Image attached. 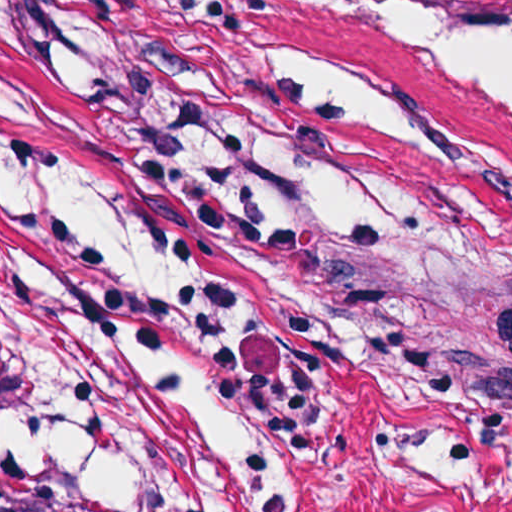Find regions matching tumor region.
Returning a JSON list of instances; mask_svg holds the SVG:
<instances>
[{"instance_id":"1","label":"tumor region","mask_w":512,"mask_h":512,"mask_svg":"<svg viewBox=\"0 0 512 512\" xmlns=\"http://www.w3.org/2000/svg\"><path fill=\"white\" fill-rule=\"evenodd\" d=\"M294 276L315 284L316 262L355 260L306 249L290 256ZM457 279L488 291L512 296V283L448 272ZM3 421L0 417V427ZM0 512H103L72 491L0 470Z\"/></svg>"}]
</instances>
